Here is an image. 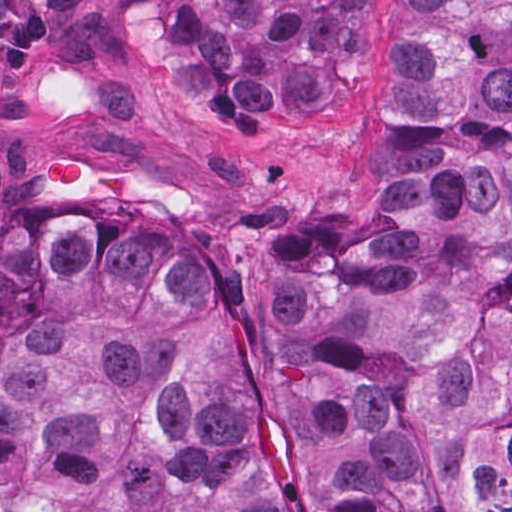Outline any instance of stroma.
<instances>
[{"label":"stroma","mask_w":512,"mask_h":512,"mask_svg":"<svg viewBox=\"0 0 512 512\" xmlns=\"http://www.w3.org/2000/svg\"><path fill=\"white\" fill-rule=\"evenodd\" d=\"M119 1H364L334 103L296 125L188 116L133 61ZM393 1L0 0V239L35 213L85 209L166 241L245 353L256 443L279 512H320L271 387L259 242L355 226L377 204L392 106ZM74 149L97 188L55 191L41 166Z\"/></svg>","instance_id":"35a3bbf8"}]
</instances>
